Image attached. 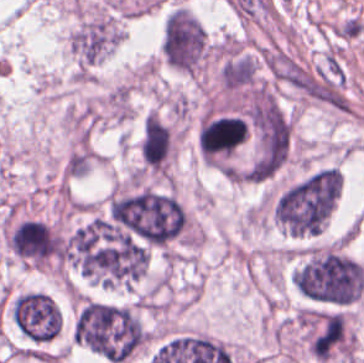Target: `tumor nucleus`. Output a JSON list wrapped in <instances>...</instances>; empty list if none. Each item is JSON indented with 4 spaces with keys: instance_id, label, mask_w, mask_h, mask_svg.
Wrapping results in <instances>:
<instances>
[{
    "instance_id": "obj_1",
    "label": "tumor nucleus",
    "mask_w": 364,
    "mask_h": 363,
    "mask_svg": "<svg viewBox=\"0 0 364 363\" xmlns=\"http://www.w3.org/2000/svg\"><path fill=\"white\" fill-rule=\"evenodd\" d=\"M78 345L110 363L127 361L147 340L132 309L81 301L73 326Z\"/></svg>"
},
{
    "instance_id": "obj_2",
    "label": "tumor nucleus",
    "mask_w": 364,
    "mask_h": 363,
    "mask_svg": "<svg viewBox=\"0 0 364 363\" xmlns=\"http://www.w3.org/2000/svg\"><path fill=\"white\" fill-rule=\"evenodd\" d=\"M124 33L120 12L94 0H80L65 35L66 51L78 62H101Z\"/></svg>"
},
{
    "instance_id": "obj_3",
    "label": "tumor nucleus",
    "mask_w": 364,
    "mask_h": 363,
    "mask_svg": "<svg viewBox=\"0 0 364 363\" xmlns=\"http://www.w3.org/2000/svg\"><path fill=\"white\" fill-rule=\"evenodd\" d=\"M210 58L209 36L203 22L184 4L163 20L162 59L184 74L203 71Z\"/></svg>"
}]
</instances>
